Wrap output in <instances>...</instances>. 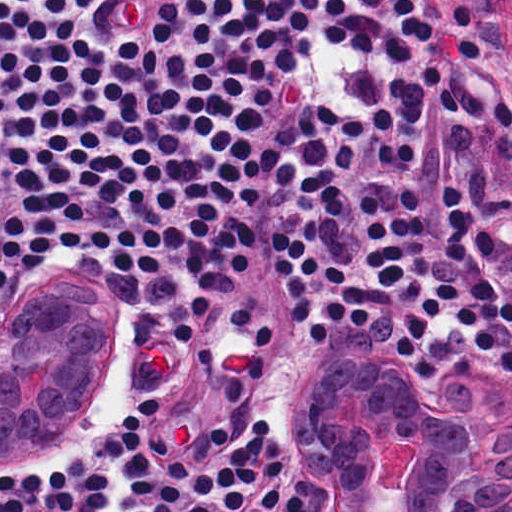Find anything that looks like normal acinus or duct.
<instances>
[{
    "label": "normal acinus or duct",
    "mask_w": 512,
    "mask_h": 512,
    "mask_svg": "<svg viewBox=\"0 0 512 512\" xmlns=\"http://www.w3.org/2000/svg\"><path fill=\"white\" fill-rule=\"evenodd\" d=\"M353 345L297 384L295 458L313 512H381L376 464L410 414L402 372ZM128 352L113 300L27 288L0 318V456L28 464L82 420ZM467 373L443 399L425 477L409 512H502L512 504V389Z\"/></svg>",
    "instance_id": "30e58d81"
}]
</instances>
